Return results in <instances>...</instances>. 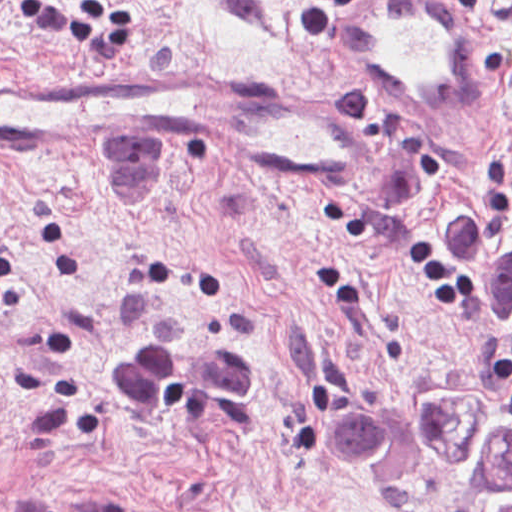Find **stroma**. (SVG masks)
<instances>
[{
  "label": "stroma",
  "instance_id": "35a3bbf8",
  "mask_svg": "<svg viewBox=\"0 0 512 512\" xmlns=\"http://www.w3.org/2000/svg\"><path fill=\"white\" fill-rule=\"evenodd\" d=\"M459 3V2H458ZM481 120L365 99L309 0H0V73H168L293 90L355 126L352 195L232 164L0 146V512H486L436 469L385 498L324 439L345 405L470 392L512 361L444 258L460 203L512 207V0Z\"/></svg>",
  "mask_w": 512,
  "mask_h": 512
}]
</instances>
